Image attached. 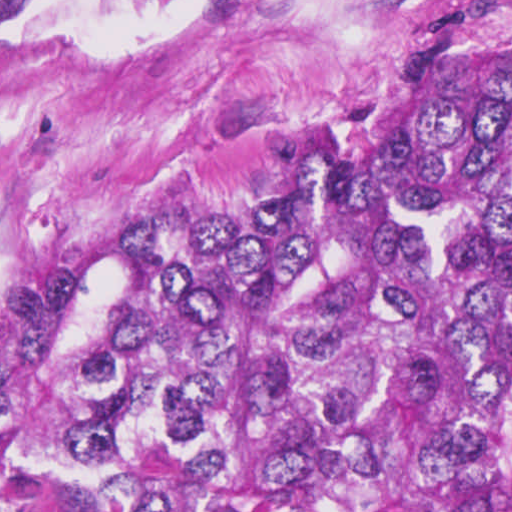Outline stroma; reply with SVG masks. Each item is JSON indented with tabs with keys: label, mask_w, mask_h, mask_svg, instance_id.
<instances>
[{
	"label": "stroma",
	"mask_w": 512,
	"mask_h": 512,
	"mask_svg": "<svg viewBox=\"0 0 512 512\" xmlns=\"http://www.w3.org/2000/svg\"><path fill=\"white\" fill-rule=\"evenodd\" d=\"M512 0H45L0 32V316L87 246L239 211Z\"/></svg>",
	"instance_id": "stroma-1"
}]
</instances>
